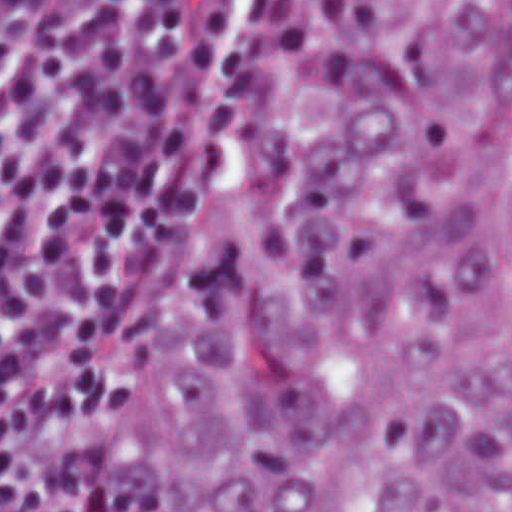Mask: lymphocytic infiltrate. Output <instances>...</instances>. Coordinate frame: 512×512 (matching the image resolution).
Listing matches in <instances>:
<instances>
[{
	"label": "lymphocytic infiltrate",
	"mask_w": 512,
	"mask_h": 512,
	"mask_svg": "<svg viewBox=\"0 0 512 512\" xmlns=\"http://www.w3.org/2000/svg\"><path fill=\"white\" fill-rule=\"evenodd\" d=\"M292 1H0V512L107 492L172 205Z\"/></svg>",
	"instance_id": "obj_1"
}]
</instances>
